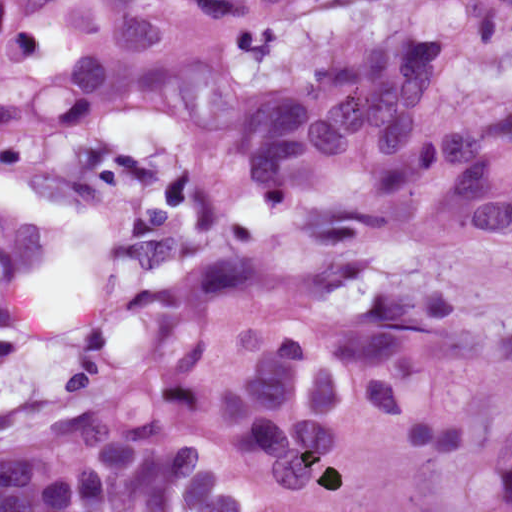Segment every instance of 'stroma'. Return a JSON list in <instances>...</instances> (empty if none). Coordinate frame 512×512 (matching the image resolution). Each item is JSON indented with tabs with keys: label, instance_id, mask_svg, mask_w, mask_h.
<instances>
[{
	"label": "stroma",
	"instance_id": "obj_1",
	"mask_svg": "<svg viewBox=\"0 0 512 512\" xmlns=\"http://www.w3.org/2000/svg\"><path fill=\"white\" fill-rule=\"evenodd\" d=\"M314 0H0V140Z\"/></svg>",
	"mask_w": 512,
	"mask_h": 512
}]
</instances>
